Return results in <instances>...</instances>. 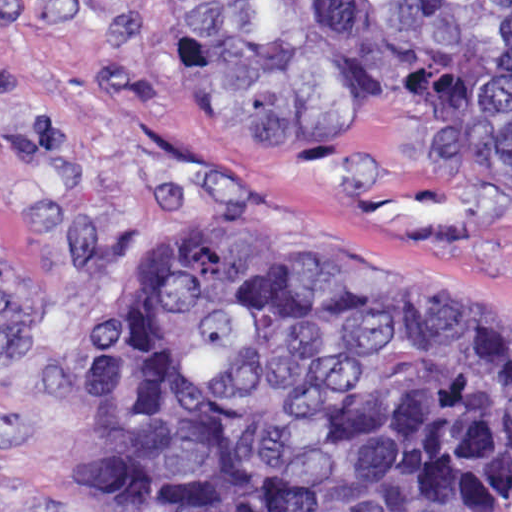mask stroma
Wrapping results in <instances>:
<instances>
[{
	"label": "stroma",
	"mask_w": 512,
	"mask_h": 512,
	"mask_svg": "<svg viewBox=\"0 0 512 512\" xmlns=\"http://www.w3.org/2000/svg\"><path fill=\"white\" fill-rule=\"evenodd\" d=\"M211 229L512 314V163H307L228 83L225 0H0V512H105L97 309Z\"/></svg>",
	"instance_id": "1"
}]
</instances>
